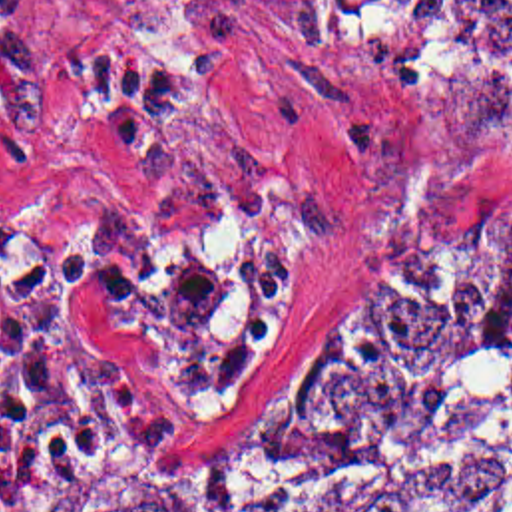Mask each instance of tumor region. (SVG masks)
Segmentation results:
<instances>
[{"instance_id":"obj_1","label":"tumor region","mask_w":512,"mask_h":512,"mask_svg":"<svg viewBox=\"0 0 512 512\" xmlns=\"http://www.w3.org/2000/svg\"><path fill=\"white\" fill-rule=\"evenodd\" d=\"M457 45L512 85V0ZM7 512H512V185L353 247L194 454L31 438Z\"/></svg>"}]
</instances>
